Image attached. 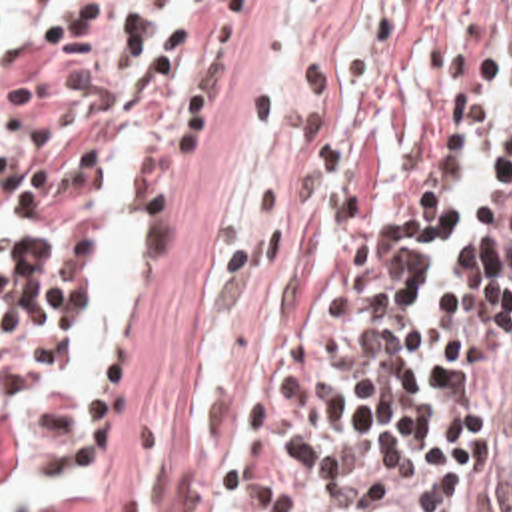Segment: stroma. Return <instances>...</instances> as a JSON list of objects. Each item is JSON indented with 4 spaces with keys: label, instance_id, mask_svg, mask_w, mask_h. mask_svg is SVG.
<instances>
[{
    "label": "stroma",
    "instance_id": "1",
    "mask_svg": "<svg viewBox=\"0 0 512 512\" xmlns=\"http://www.w3.org/2000/svg\"><path fill=\"white\" fill-rule=\"evenodd\" d=\"M207 2V56L164 176L116 206L76 254V335L98 228L132 206L144 218V283L118 373L88 431L98 491L48 512H213V417L267 268L281 152L351 2L512 0H0Z\"/></svg>",
    "mask_w": 512,
    "mask_h": 512
}]
</instances>
